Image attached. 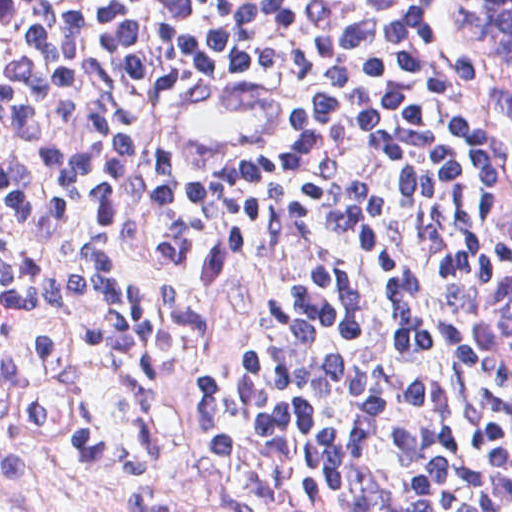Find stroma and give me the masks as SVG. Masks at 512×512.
Returning a JSON list of instances; mask_svg holds the SVG:
<instances>
[{
  "label": "stroma",
  "mask_w": 512,
  "mask_h": 512,
  "mask_svg": "<svg viewBox=\"0 0 512 512\" xmlns=\"http://www.w3.org/2000/svg\"><path fill=\"white\" fill-rule=\"evenodd\" d=\"M451 1L435 0L443 55L461 72L512 96L499 73L451 19ZM33 310L10 322L20 364L46 401L48 414L34 453L0 394V512H124L112 500L136 498L175 512H248L232 483L194 394L171 374L134 357L88 321L67 283L0 259ZM512 268L490 272L474 292L471 366L492 402L512 413V348L501 337L503 295ZM48 336L51 360L34 353ZM109 444L136 434L179 486L134 476H103L56 465L72 459L82 424Z\"/></svg>",
  "instance_id": "35a3bbf8"
}]
</instances>
